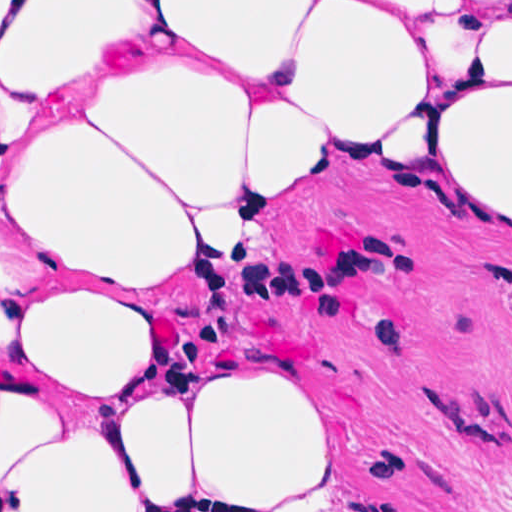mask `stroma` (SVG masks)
<instances>
[{
    "label": "stroma",
    "instance_id": "1",
    "mask_svg": "<svg viewBox=\"0 0 512 512\" xmlns=\"http://www.w3.org/2000/svg\"><path fill=\"white\" fill-rule=\"evenodd\" d=\"M323 1L360 83L426 28L512 0ZM143 360L103 395L61 394L0 353V382L100 417L179 382L277 373L314 396L332 467L240 508L512 512V229L453 185L429 127L332 151L242 218L227 260L146 291Z\"/></svg>",
    "mask_w": 512,
    "mask_h": 512
}]
</instances>
